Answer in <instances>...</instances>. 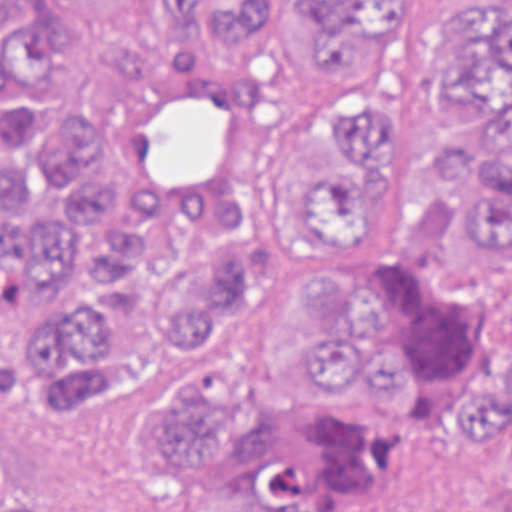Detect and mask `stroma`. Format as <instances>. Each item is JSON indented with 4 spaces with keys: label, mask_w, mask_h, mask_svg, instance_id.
Here are the masks:
<instances>
[{
    "label": "stroma",
    "mask_w": 512,
    "mask_h": 512,
    "mask_svg": "<svg viewBox=\"0 0 512 512\" xmlns=\"http://www.w3.org/2000/svg\"><path fill=\"white\" fill-rule=\"evenodd\" d=\"M452 2L384 0L375 25L347 40L298 19L251 57L223 36L163 19L166 0H0V29L33 9L56 32L61 89L82 109L139 88L167 93L140 115L117 173L127 198L154 210L184 216L217 199L245 216L256 274L234 327V361L258 403L282 390L254 361L260 286L303 246V218L271 171V142L331 72L355 77L387 97L391 213L443 197L455 137L476 116L454 97L444 48ZM490 131L486 113L471 126L474 175L464 194L432 215L379 217L366 257L393 260L397 276L498 319L512 305V252L484 245L468 217ZM192 343L128 395H72L16 329L0 357L3 463L44 488L50 512H259L198 499L167 480L149 450L144 422L183 372ZM465 347L512 374V318ZM333 509L512 512V448L466 417L435 422L376 463Z\"/></svg>",
    "instance_id": "35a3bbf8"
}]
</instances>
